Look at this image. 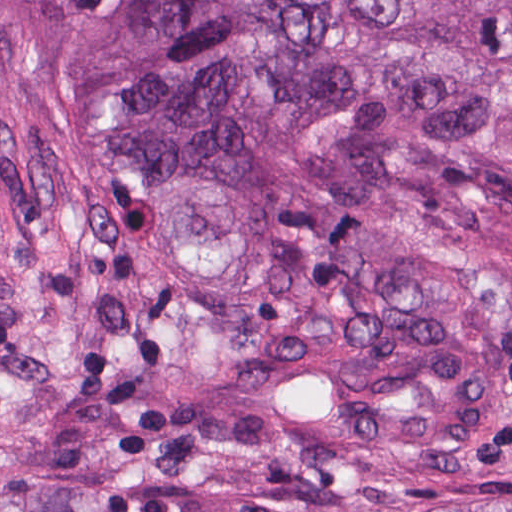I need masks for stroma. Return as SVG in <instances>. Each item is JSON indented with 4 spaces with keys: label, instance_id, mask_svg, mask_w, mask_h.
Returning a JSON list of instances; mask_svg holds the SVG:
<instances>
[{
    "label": "stroma",
    "instance_id": "obj_1",
    "mask_svg": "<svg viewBox=\"0 0 512 512\" xmlns=\"http://www.w3.org/2000/svg\"><path fill=\"white\" fill-rule=\"evenodd\" d=\"M429 251L512 304V187L429 193ZM59 481L118 512H453L512 479L376 441L191 413L116 134L1 69L0 512Z\"/></svg>",
    "mask_w": 512,
    "mask_h": 512
}]
</instances>
